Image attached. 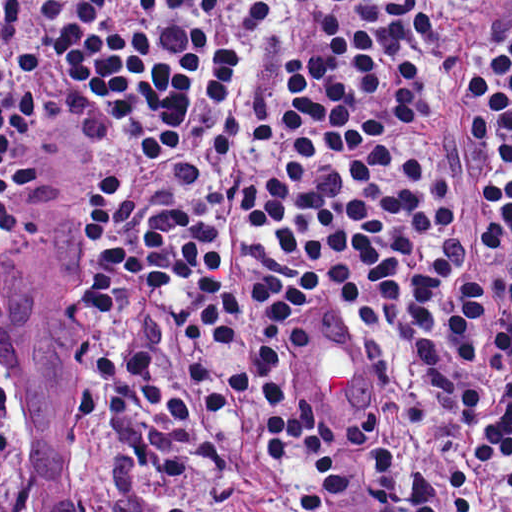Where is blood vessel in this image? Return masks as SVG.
Listing matches in <instances>:
<instances>
[{
	"instance_id": "obj_1",
	"label": "blood vessel",
	"mask_w": 512,
	"mask_h": 512,
	"mask_svg": "<svg viewBox=\"0 0 512 512\" xmlns=\"http://www.w3.org/2000/svg\"><path fill=\"white\" fill-rule=\"evenodd\" d=\"M301 343L305 362L341 394L353 415L377 411L380 376L357 333L337 322H308Z\"/></svg>"
}]
</instances>
